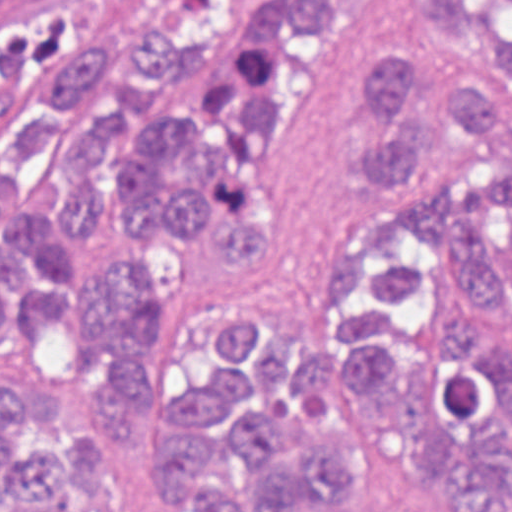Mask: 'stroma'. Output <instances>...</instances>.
I'll list each match as a JSON object with an SVG mask.
<instances>
[{"instance_id": "1", "label": "stroma", "mask_w": 512, "mask_h": 512, "mask_svg": "<svg viewBox=\"0 0 512 512\" xmlns=\"http://www.w3.org/2000/svg\"><path fill=\"white\" fill-rule=\"evenodd\" d=\"M276 0H232L214 42V61L164 87L144 126L198 123L217 78L243 55L257 11ZM218 0H110L103 42L107 73L68 103L65 119L41 157L9 170L12 136L21 123L50 109L43 85L0 95V208L40 202L59 242L78 247L54 222V205L78 186L60 162V142L83 124L115 113L130 88V39L156 21L201 33ZM346 14L322 35L289 43L292 81L273 114L259 158V196L276 225L273 243L247 259H228L210 230L178 236L155 219L149 248L163 276L161 292L139 338L149 384L173 375L193 345L225 319L252 318L253 329L275 324L308 304L323 272L347 249L365 216V182L350 148L365 140L359 114L364 64L395 47L431 49L412 29L408 0H344ZM502 125L473 132L497 165L512 164V87L492 90ZM24 386H117L112 351L84 364L76 352V318L64 302L46 305L33 331L17 309L0 320V383Z\"/></svg>"}]
</instances>
